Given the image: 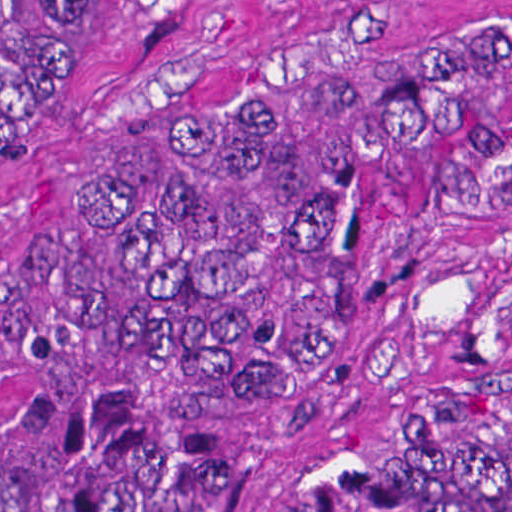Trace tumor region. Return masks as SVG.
<instances>
[{
    "label": "tumor region",
    "mask_w": 512,
    "mask_h": 512,
    "mask_svg": "<svg viewBox=\"0 0 512 512\" xmlns=\"http://www.w3.org/2000/svg\"><path fill=\"white\" fill-rule=\"evenodd\" d=\"M77 0H1V115ZM512 0H415L136 155L61 246L1 249V512H512V400L312 412L413 198L512 199V132L455 116Z\"/></svg>",
    "instance_id": "obj_1"
}]
</instances>
